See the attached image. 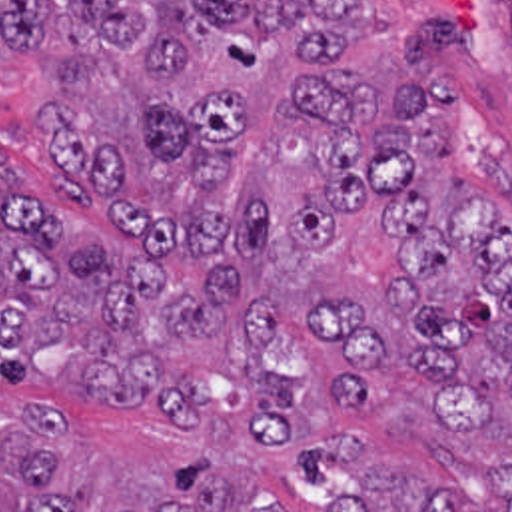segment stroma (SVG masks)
Listing matches in <instances>:
<instances>
[{"instance_id": "35a3bbf8", "label": "stroma", "mask_w": 512, "mask_h": 512, "mask_svg": "<svg viewBox=\"0 0 512 512\" xmlns=\"http://www.w3.org/2000/svg\"><path fill=\"white\" fill-rule=\"evenodd\" d=\"M392 25L428 11H452L458 47L438 59L436 77L458 89L448 123V147L468 193L512 231V0H363ZM47 75L35 47L0 45V157L33 203L87 245L123 253L165 271L173 283L197 285L213 271L233 269L245 300H271L281 322L267 362L283 378L301 374L305 388L295 412L305 430L299 444H253V400L231 372L199 380L205 396L191 424L169 420L153 404H125L87 394L79 352L53 350L37 380L15 384L0 376V414L25 402L49 406L65 430V466L57 484L69 488L77 468L97 480V512L145 504L163 474L205 458L255 484L273 508L327 506L349 498L365 470L398 468L456 494L472 512H510L512 402L504 396L482 430L456 428L438 408L430 384L406 366H382L372 378L370 404H349L331 392L343 360L311 326V298L337 293L366 298L384 338L404 340L408 320L388 310L386 265L392 237L374 215H345L337 237L299 245L297 275L273 273L255 257L233 253L165 255L147 259L123 227L99 225L49 185V147L31 115Z\"/></svg>"}]
</instances>
